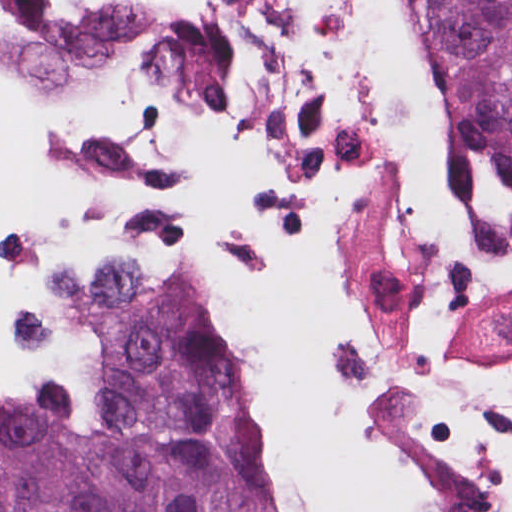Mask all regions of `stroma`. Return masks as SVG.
<instances>
[{
    "label": "stroma",
    "mask_w": 512,
    "mask_h": 512,
    "mask_svg": "<svg viewBox=\"0 0 512 512\" xmlns=\"http://www.w3.org/2000/svg\"><path fill=\"white\" fill-rule=\"evenodd\" d=\"M77 256L0 246L2 265L40 284L44 298L34 308H18L10 316L8 329L13 344L39 359L41 372L25 389L0 391V407L10 394L22 391H57L79 407L91 392V370L64 328L56 288L62 269ZM229 324L243 354L230 320ZM277 512H290L278 490Z\"/></svg>",
    "instance_id": "obj_1"
}]
</instances>
